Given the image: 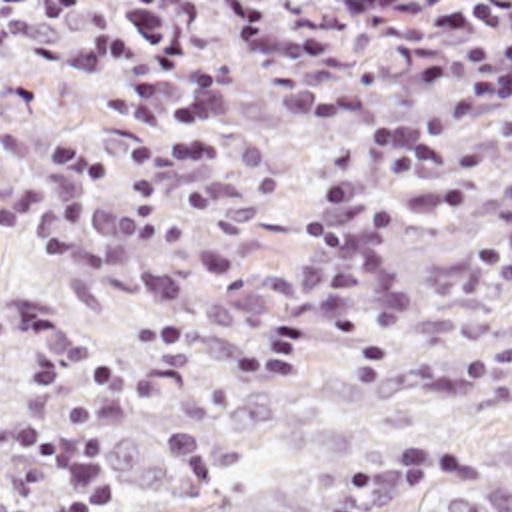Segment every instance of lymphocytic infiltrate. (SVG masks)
Instances as JSON below:
<instances>
[{
  "instance_id": "f902f5d3",
  "label": "lymphocytic infiltrate",
  "mask_w": 512,
  "mask_h": 512,
  "mask_svg": "<svg viewBox=\"0 0 512 512\" xmlns=\"http://www.w3.org/2000/svg\"><path fill=\"white\" fill-rule=\"evenodd\" d=\"M0 453L51 471L53 495L45 512H103L113 505V481L87 435L27 417H0Z\"/></svg>"
}]
</instances>
